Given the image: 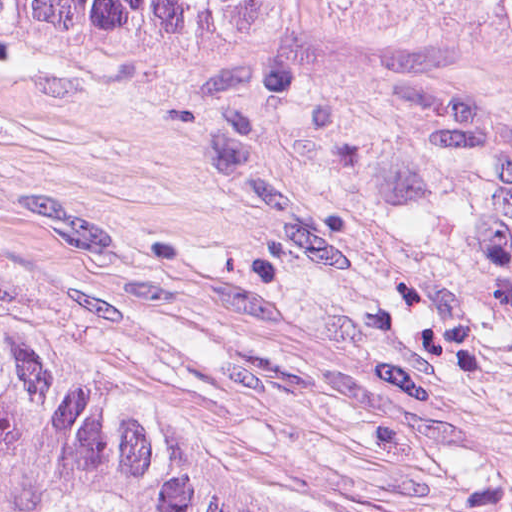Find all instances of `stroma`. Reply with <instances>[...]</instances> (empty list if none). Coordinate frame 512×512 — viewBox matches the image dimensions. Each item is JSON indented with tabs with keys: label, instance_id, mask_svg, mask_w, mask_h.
Here are the masks:
<instances>
[{
	"label": "stroma",
	"instance_id": "35a3bbf8",
	"mask_svg": "<svg viewBox=\"0 0 512 512\" xmlns=\"http://www.w3.org/2000/svg\"><path fill=\"white\" fill-rule=\"evenodd\" d=\"M0 278L380 512H512V34L0 29Z\"/></svg>",
	"mask_w": 512,
	"mask_h": 512
}]
</instances>
